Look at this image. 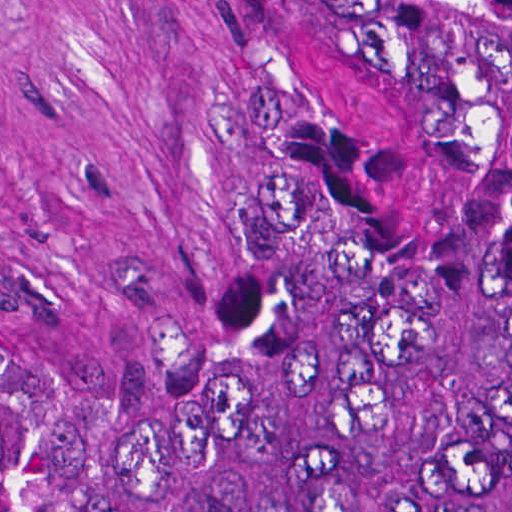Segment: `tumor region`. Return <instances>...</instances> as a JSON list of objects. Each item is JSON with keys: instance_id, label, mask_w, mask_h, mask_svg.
<instances>
[{"instance_id": "e687c5a6", "label": "tumor region", "mask_w": 512, "mask_h": 512, "mask_svg": "<svg viewBox=\"0 0 512 512\" xmlns=\"http://www.w3.org/2000/svg\"><path fill=\"white\" fill-rule=\"evenodd\" d=\"M0 512H512V0H230L201 308L0 305Z\"/></svg>"}]
</instances>
